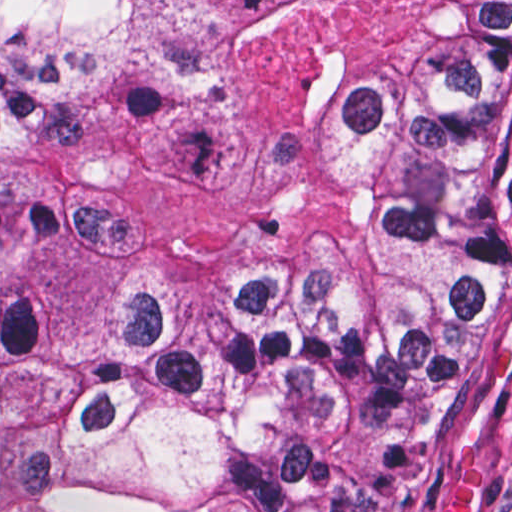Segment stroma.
<instances>
[{
    "instance_id": "35a3bbf8",
    "label": "stroma",
    "mask_w": 512,
    "mask_h": 512,
    "mask_svg": "<svg viewBox=\"0 0 512 512\" xmlns=\"http://www.w3.org/2000/svg\"><path fill=\"white\" fill-rule=\"evenodd\" d=\"M0 1H512V0H0ZM512 326V209L483 334L403 455L395 488L367 512H442L475 471V512H512V363L490 375V351Z\"/></svg>"
}]
</instances>
